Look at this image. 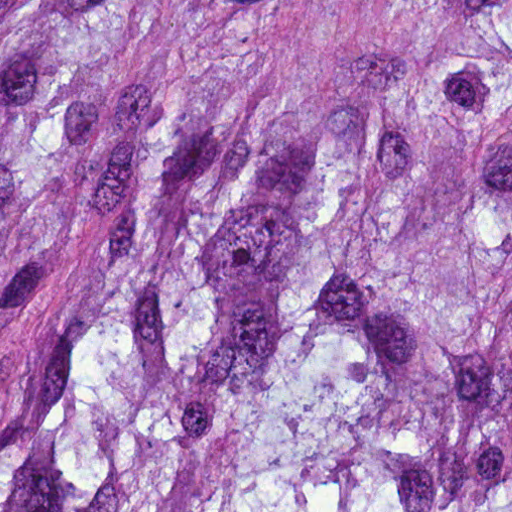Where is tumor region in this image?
I'll return each mask as SVG.
<instances>
[{"label": "tumor region", "instance_id": "e687c5a6", "mask_svg": "<svg viewBox=\"0 0 512 512\" xmlns=\"http://www.w3.org/2000/svg\"><path fill=\"white\" fill-rule=\"evenodd\" d=\"M0 512H512V0H0Z\"/></svg>", "mask_w": 512, "mask_h": 512}]
</instances>
